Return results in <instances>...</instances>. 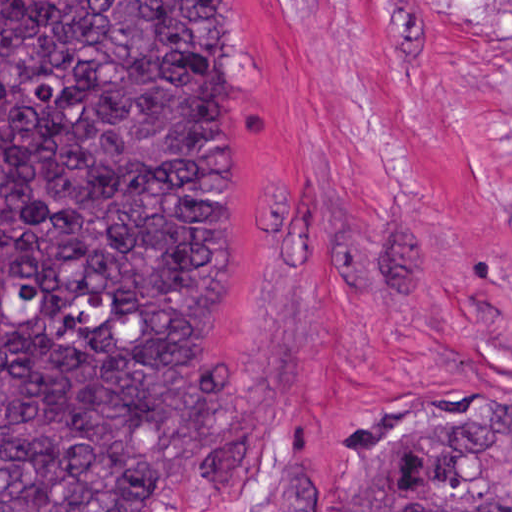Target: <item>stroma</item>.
I'll return each instance as SVG.
<instances>
[{
    "label": "stroma",
    "instance_id": "obj_1",
    "mask_svg": "<svg viewBox=\"0 0 512 512\" xmlns=\"http://www.w3.org/2000/svg\"><path fill=\"white\" fill-rule=\"evenodd\" d=\"M215 1L221 299L187 375L260 470L188 512H344L404 401L512 410V0Z\"/></svg>",
    "mask_w": 512,
    "mask_h": 512
}]
</instances>
